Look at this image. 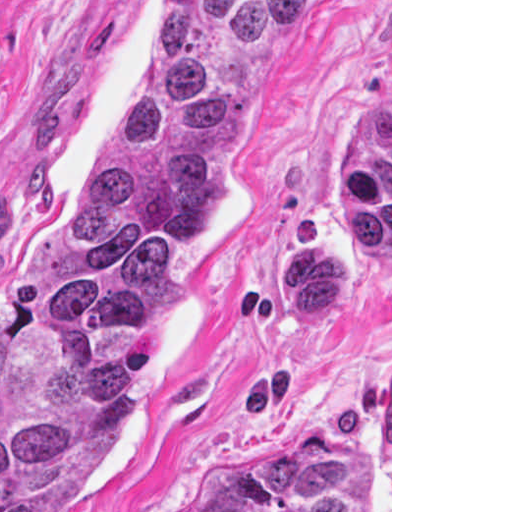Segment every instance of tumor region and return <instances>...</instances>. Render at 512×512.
<instances>
[{
    "label": "tumor region",
    "instance_id": "e687c5a6",
    "mask_svg": "<svg viewBox=\"0 0 512 512\" xmlns=\"http://www.w3.org/2000/svg\"><path fill=\"white\" fill-rule=\"evenodd\" d=\"M305 0H153L82 202L0 282V512H56L120 445L154 322ZM179 512H370L346 442L275 430Z\"/></svg>",
    "mask_w": 512,
    "mask_h": 512
}]
</instances>
